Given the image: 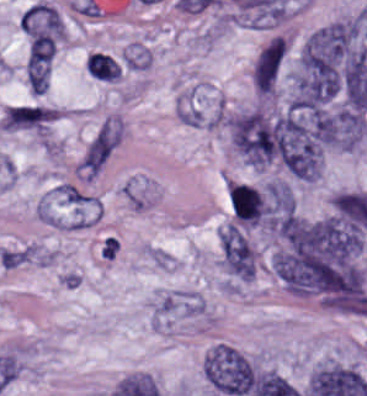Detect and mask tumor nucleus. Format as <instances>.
I'll return each instance as SVG.
<instances>
[{
  "instance_id": "obj_1",
  "label": "tumor nucleus",
  "mask_w": 367,
  "mask_h": 396,
  "mask_svg": "<svg viewBox=\"0 0 367 396\" xmlns=\"http://www.w3.org/2000/svg\"><path fill=\"white\" fill-rule=\"evenodd\" d=\"M287 54L286 42L275 35L260 49L252 66V85L258 95L273 94Z\"/></svg>"
}]
</instances>
